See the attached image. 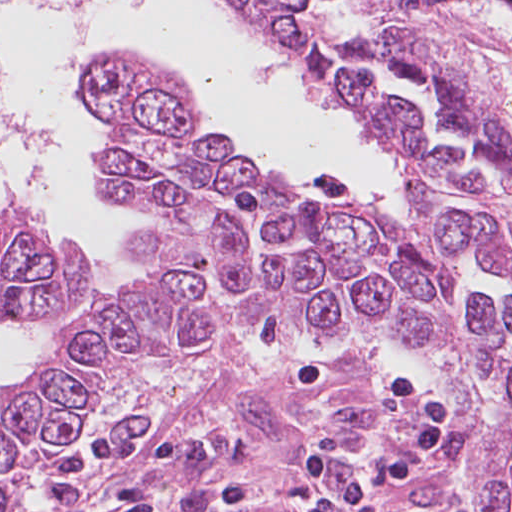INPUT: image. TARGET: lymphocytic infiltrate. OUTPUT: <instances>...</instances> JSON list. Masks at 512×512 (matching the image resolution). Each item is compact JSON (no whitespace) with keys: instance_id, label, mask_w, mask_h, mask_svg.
<instances>
[{"instance_id":"1","label":"lymphocytic infiltrate","mask_w":512,"mask_h":512,"mask_svg":"<svg viewBox=\"0 0 512 512\" xmlns=\"http://www.w3.org/2000/svg\"><path fill=\"white\" fill-rule=\"evenodd\" d=\"M334 371L321 357H307L292 382L299 391L332 384ZM389 396L406 409L407 425L397 442L356 454L342 433L324 426L303 445L296 473L305 489L291 512H384L383 492L419 480L456 425L444 396L424 376L407 372L390 383ZM64 512H86V495L96 470L115 469L110 512H159L150 482L184 465L189 445L178 438L95 435L43 450Z\"/></svg>"}]
</instances>
